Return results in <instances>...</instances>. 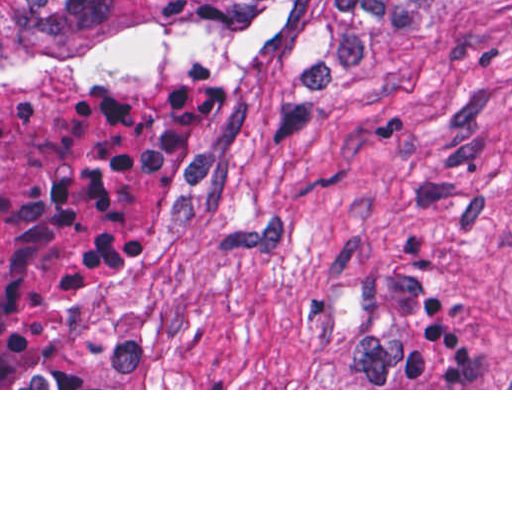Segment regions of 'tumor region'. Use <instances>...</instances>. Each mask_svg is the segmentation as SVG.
I'll use <instances>...</instances> for the list:
<instances>
[{
    "label": "tumor region",
    "instance_id": "obj_1",
    "mask_svg": "<svg viewBox=\"0 0 512 512\" xmlns=\"http://www.w3.org/2000/svg\"><path fill=\"white\" fill-rule=\"evenodd\" d=\"M445 0H0V84L102 59L193 54L295 109L392 86L403 28Z\"/></svg>",
    "mask_w": 512,
    "mask_h": 512
}]
</instances>
